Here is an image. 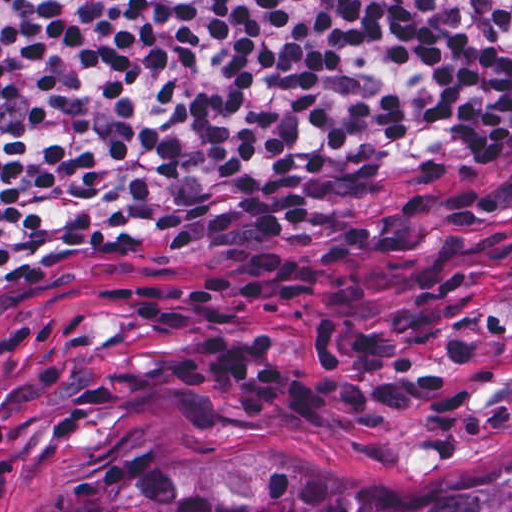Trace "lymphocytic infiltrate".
<instances>
[{"label":"lymphocytic infiltrate","instance_id":"1","mask_svg":"<svg viewBox=\"0 0 512 512\" xmlns=\"http://www.w3.org/2000/svg\"><path fill=\"white\" fill-rule=\"evenodd\" d=\"M512 133V0H0V280L43 253L163 239L277 242L321 191ZM98 301L197 328L177 389L247 420L328 395L231 323L266 281L182 302L113 278Z\"/></svg>","mask_w":512,"mask_h":512}]
</instances>
